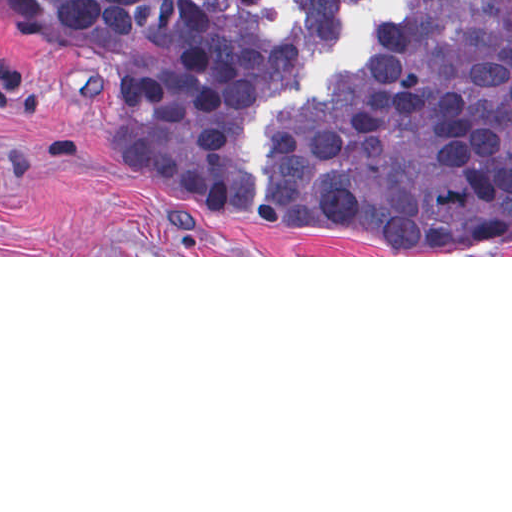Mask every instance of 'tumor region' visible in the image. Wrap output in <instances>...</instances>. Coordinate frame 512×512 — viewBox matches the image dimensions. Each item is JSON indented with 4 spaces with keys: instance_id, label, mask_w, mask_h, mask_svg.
<instances>
[{
    "instance_id": "e687c5a6",
    "label": "tumor region",
    "mask_w": 512,
    "mask_h": 512,
    "mask_svg": "<svg viewBox=\"0 0 512 512\" xmlns=\"http://www.w3.org/2000/svg\"><path fill=\"white\" fill-rule=\"evenodd\" d=\"M362 1L293 3L337 47ZM0 4L62 41L145 195L207 222L376 255L512 250V0H407L321 105L273 119L254 214L237 181V118L304 69L299 35L267 39L255 0Z\"/></svg>"
}]
</instances>
